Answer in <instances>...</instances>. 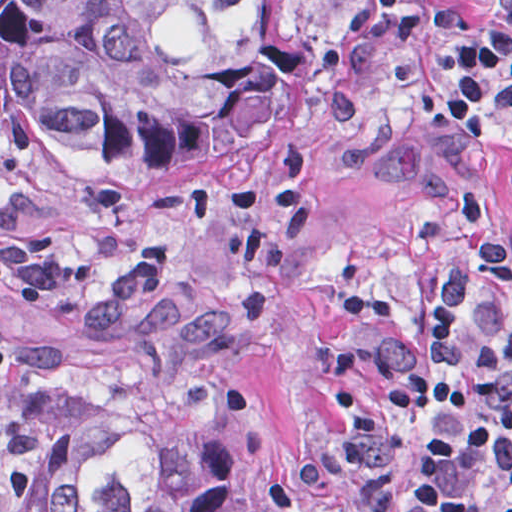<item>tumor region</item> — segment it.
<instances>
[{
    "mask_svg": "<svg viewBox=\"0 0 512 512\" xmlns=\"http://www.w3.org/2000/svg\"><path fill=\"white\" fill-rule=\"evenodd\" d=\"M306 41L261 0H0V161L196 173L282 118ZM232 304L147 267L16 340L0 512H251L266 425L228 371Z\"/></svg>",
    "mask_w": 512,
    "mask_h": 512,
    "instance_id": "e687c5a6",
    "label": "tumor region"
}]
</instances>
